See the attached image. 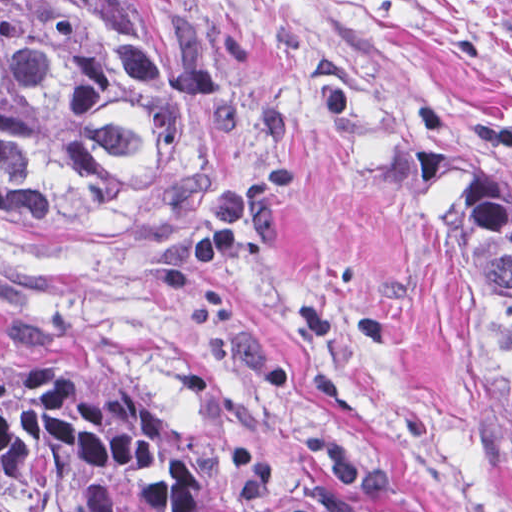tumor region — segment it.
Returning a JSON list of instances; mask_svg holds the SVG:
<instances>
[{
    "mask_svg": "<svg viewBox=\"0 0 512 512\" xmlns=\"http://www.w3.org/2000/svg\"><path fill=\"white\" fill-rule=\"evenodd\" d=\"M215 92L176 0H0V228L137 234L214 188ZM435 245L512 418V174L464 172ZM0 512H240L85 402L0 376Z\"/></svg>",
    "mask_w": 512,
    "mask_h": 512,
    "instance_id": "1",
    "label": "tumor region"
}]
</instances>
